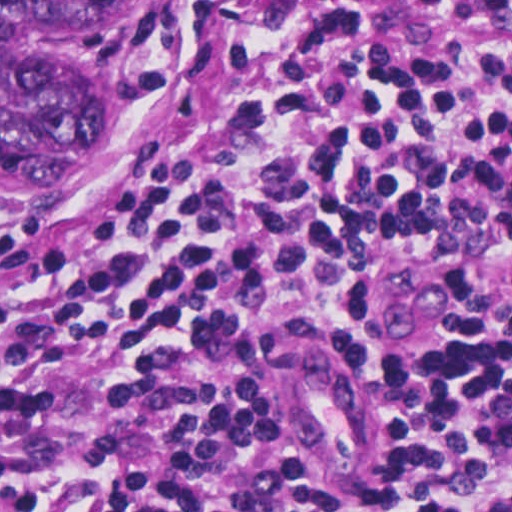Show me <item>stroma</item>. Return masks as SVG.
<instances>
[{
	"mask_svg": "<svg viewBox=\"0 0 512 512\" xmlns=\"http://www.w3.org/2000/svg\"><path fill=\"white\" fill-rule=\"evenodd\" d=\"M188 0H114L106 20L120 68L114 124L86 161L31 196H0V227H24L57 217L128 178L156 150L178 89L163 75L166 54ZM251 12H269L279 0H225ZM366 25L376 42L396 53H421L446 40L483 53H500L507 25L472 12L435 11L423 0H317ZM512 210V207H509ZM320 278L317 300L330 316H353L359 303L335 274ZM435 289L449 302L453 341L471 338L481 323L475 302L452 276L439 271ZM512 299V292H502Z\"/></svg>",
	"mask_w": 512,
	"mask_h": 512,
	"instance_id": "obj_1",
	"label": "stroma"
}]
</instances>
